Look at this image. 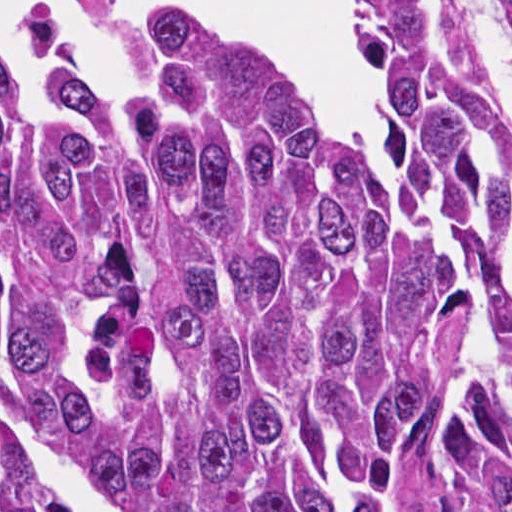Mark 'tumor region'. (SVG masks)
<instances>
[{"instance_id":"obj_1","label":"tumor region","mask_w":512,"mask_h":512,"mask_svg":"<svg viewBox=\"0 0 512 512\" xmlns=\"http://www.w3.org/2000/svg\"><path fill=\"white\" fill-rule=\"evenodd\" d=\"M341 2L382 180L235 30L170 18L135 115L0 35V396L129 512H512V120L451 0ZM0 512H64L1 425Z\"/></svg>"}]
</instances>
